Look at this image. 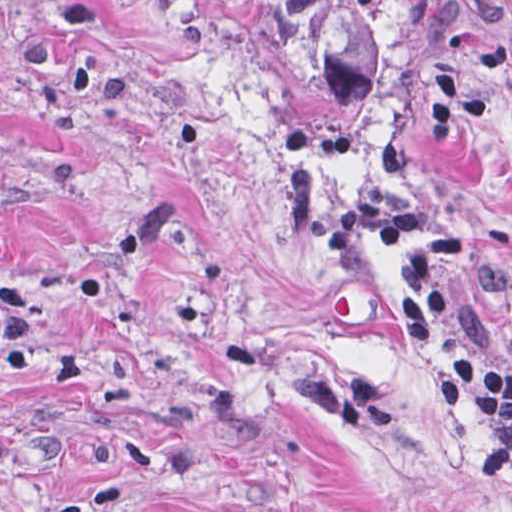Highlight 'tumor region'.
<instances>
[{
	"instance_id": "e687c5a6",
	"label": "tumor region",
	"mask_w": 512,
	"mask_h": 512,
	"mask_svg": "<svg viewBox=\"0 0 512 512\" xmlns=\"http://www.w3.org/2000/svg\"><path fill=\"white\" fill-rule=\"evenodd\" d=\"M292 197L403 295L512 453V8L247 0Z\"/></svg>"
}]
</instances>
